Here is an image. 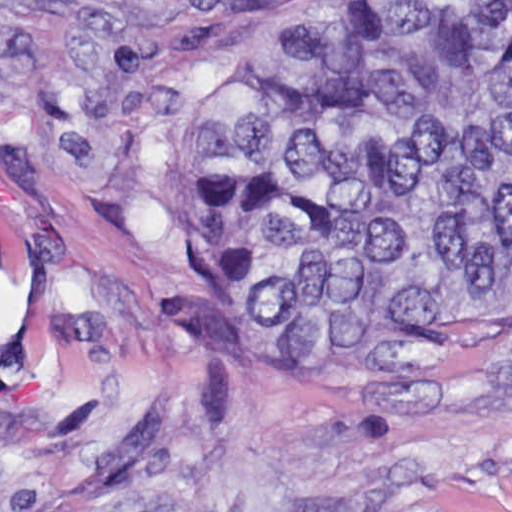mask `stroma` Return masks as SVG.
Instances as JSON below:
<instances>
[{
  "instance_id": "35a3bbf8",
  "label": "stroma",
  "mask_w": 512,
  "mask_h": 512,
  "mask_svg": "<svg viewBox=\"0 0 512 512\" xmlns=\"http://www.w3.org/2000/svg\"><path fill=\"white\" fill-rule=\"evenodd\" d=\"M302 0H0V512H512V295L165 232Z\"/></svg>"
}]
</instances>
